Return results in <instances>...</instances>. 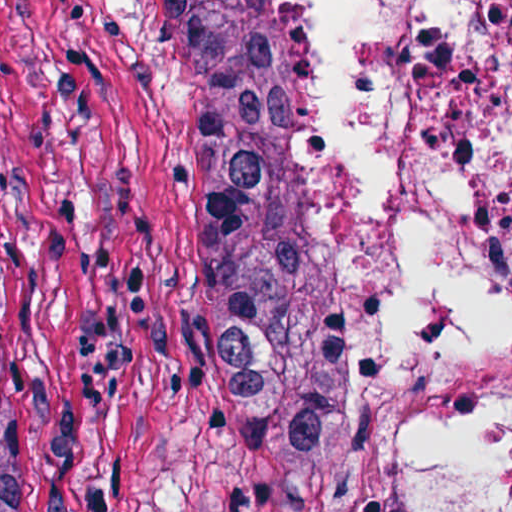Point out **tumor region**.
I'll use <instances>...</instances> for the list:
<instances>
[{"mask_svg": "<svg viewBox=\"0 0 512 512\" xmlns=\"http://www.w3.org/2000/svg\"><path fill=\"white\" fill-rule=\"evenodd\" d=\"M198 97L228 296L287 512H384L353 403L330 225L297 156L302 67L266 0H169Z\"/></svg>", "mask_w": 512, "mask_h": 512, "instance_id": "tumor-region-1", "label": "tumor region"}]
</instances>
